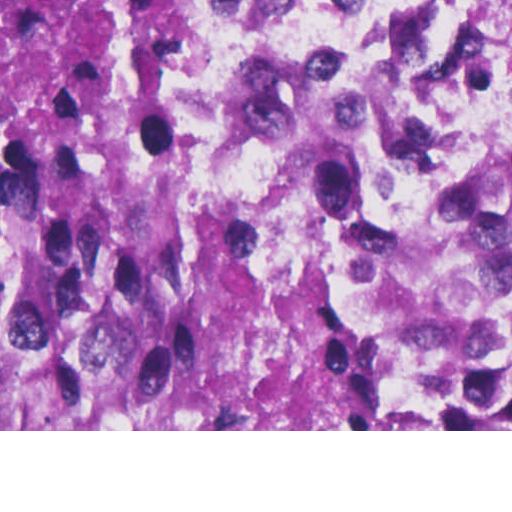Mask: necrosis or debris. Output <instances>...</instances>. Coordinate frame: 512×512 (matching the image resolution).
Returning a JSON list of instances; mask_svg holds the SVG:
<instances>
[{
	"instance_id": "4bbe7bcc",
	"label": "necrosis or debris",
	"mask_w": 512,
	"mask_h": 512,
	"mask_svg": "<svg viewBox=\"0 0 512 512\" xmlns=\"http://www.w3.org/2000/svg\"><path fill=\"white\" fill-rule=\"evenodd\" d=\"M208 159L399 394L512 419V0H241Z\"/></svg>"
}]
</instances>
